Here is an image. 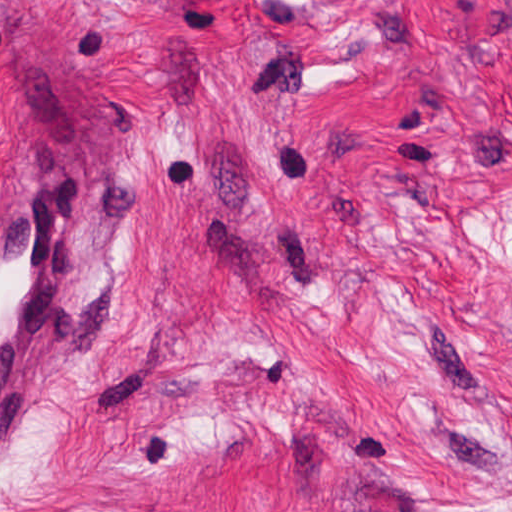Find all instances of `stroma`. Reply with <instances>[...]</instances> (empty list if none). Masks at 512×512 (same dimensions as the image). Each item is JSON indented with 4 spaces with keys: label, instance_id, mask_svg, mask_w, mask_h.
Here are the masks:
<instances>
[{
    "label": "stroma",
    "instance_id": "35a3bbf8",
    "mask_svg": "<svg viewBox=\"0 0 512 512\" xmlns=\"http://www.w3.org/2000/svg\"><path fill=\"white\" fill-rule=\"evenodd\" d=\"M67 159L0 512H512V0H0V185Z\"/></svg>",
    "mask_w": 512,
    "mask_h": 512
}]
</instances>
